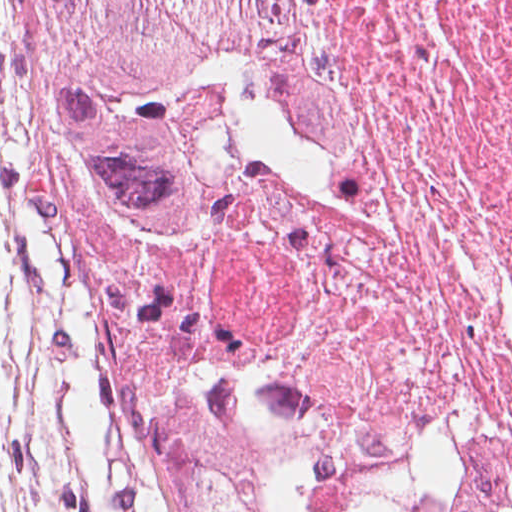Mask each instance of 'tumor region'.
<instances>
[{"label": "tumor region", "instance_id": "tumor-region-1", "mask_svg": "<svg viewBox=\"0 0 512 512\" xmlns=\"http://www.w3.org/2000/svg\"><path fill=\"white\" fill-rule=\"evenodd\" d=\"M37 234L120 478L110 512H281L191 281L218 195L354 142L296 0H23Z\"/></svg>", "mask_w": 512, "mask_h": 512}]
</instances>
